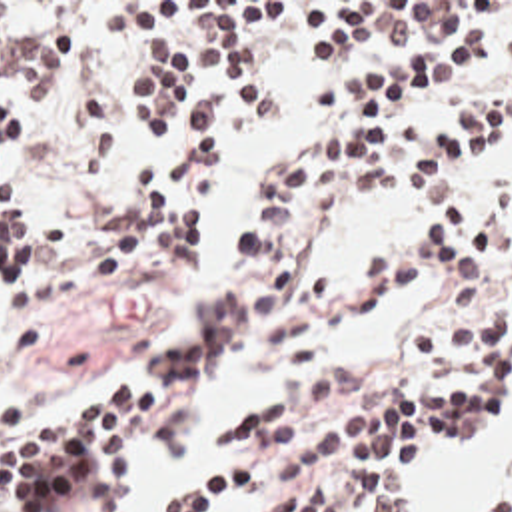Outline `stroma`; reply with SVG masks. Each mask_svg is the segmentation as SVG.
Wrapping results in <instances>:
<instances>
[{
  "mask_svg": "<svg viewBox=\"0 0 512 512\" xmlns=\"http://www.w3.org/2000/svg\"><path fill=\"white\" fill-rule=\"evenodd\" d=\"M0 2H84L78 22L76 66L54 96H38L34 82L0 68L5 80L1 106L26 102L34 110V144L13 174L7 204L30 218V258L52 264L62 286H76L70 302L21 317L0 335V397L28 423L68 421L124 393L138 377L160 363L164 351L194 323L210 294L236 276L234 224L240 210L268 184L266 164L318 146L342 112L310 116V90L372 74L400 58L414 30H386L364 36L344 64L304 62L298 34L288 24L248 30V68L262 86L270 116L252 122L236 108V96L222 82L204 76L192 82L184 104L174 112L164 150H148L136 120L126 112L132 86L156 76L158 58H134L136 30L122 20L124 6L156 10L164 16L178 2H454L460 20L452 36L488 34L490 60L466 82L406 106L430 128L466 130L474 108L510 106V134L496 146L460 164L480 196L512 186V62H500V38L512 28V0H0ZM218 142V160L188 176L184 208L202 218L198 256L174 254L156 242L154 260L126 272L120 284H102L96 256L134 218L136 176L150 160L192 142ZM478 154V152H466ZM432 226L426 188L400 190L370 200L336 218L308 252V270L342 274L370 250L396 246ZM504 290L512 310V278L456 286L436 270L358 315L352 327L324 345V359L288 363L256 353L250 337L212 371L188 381L170 401L162 419L118 457L124 512H130V485L140 457L182 441L184 431L208 449V469L168 499L206 487L234 467L214 451L212 437L226 415L266 393L324 381L344 363H364L386 383H420L424 369L414 353L422 317L448 296L472 288ZM512 433L474 451H428L412 477L406 512H418L438 459L484 461L502 453ZM512 449V445H510ZM512 491V483L468 503L462 512H484ZM230 499L238 512H272L276 479H246Z\"/></svg>",
  "mask_w": 512,
  "mask_h": 512,
  "instance_id": "35a3bbf8",
  "label": "stroma"
}]
</instances>
